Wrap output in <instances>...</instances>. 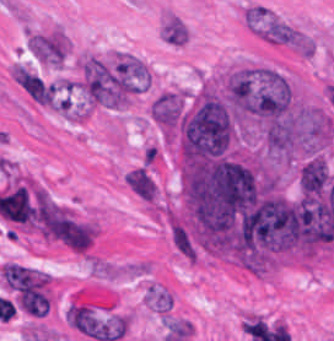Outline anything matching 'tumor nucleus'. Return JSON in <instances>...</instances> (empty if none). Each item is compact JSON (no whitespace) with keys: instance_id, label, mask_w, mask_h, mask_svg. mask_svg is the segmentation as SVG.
<instances>
[{"instance_id":"2f306a5c","label":"tumor nucleus","mask_w":334,"mask_h":341,"mask_svg":"<svg viewBox=\"0 0 334 341\" xmlns=\"http://www.w3.org/2000/svg\"><path fill=\"white\" fill-rule=\"evenodd\" d=\"M221 94L238 120L271 121L293 106L287 81L266 67H235L225 77Z\"/></svg>"},{"instance_id":"8643909e","label":"tumor nucleus","mask_w":334,"mask_h":341,"mask_svg":"<svg viewBox=\"0 0 334 341\" xmlns=\"http://www.w3.org/2000/svg\"><path fill=\"white\" fill-rule=\"evenodd\" d=\"M184 109L181 97L174 92H161L150 103L153 123L171 136L177 131Z\"/></svg>"},{"instance_id":"5ab6c2c4","label":"tumor nucleus","mask_w":334,"mask_h":341,"mask_svg":"<svg viewBox=\"0 0 334 341\" xmlns=\"http://www.w3.org/2000/svg\"><path fill=\"white\" fill-rule=\"evenodd\" d=\"M125 181L131 191L140 199L154 201L156 184L146 165H139L128 172Z\"/></svg>"}]
</instances>
